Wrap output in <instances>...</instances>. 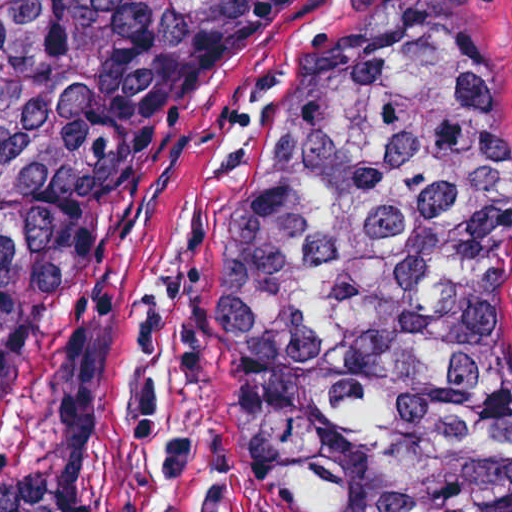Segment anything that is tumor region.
<instances>
[{
	"label": "tumor region",
	"instance_id": "tumor-region-1",
	"mask_svg": "<svg viewBox=\"0 0 512 512\" xmlns=\"http://www.w3.org/2000/svg\"><path fill=\"white\" fill-rule=\"evenodd\" d=\"M290 0H0V398L142 124ZM210 347L272 512H512V105L450 55L334 61L217 232ZM143 271L58 357L60 452L0 512H79Z\"/></svg>",
	"mask_w": 512,
	"mask_h": 512
}]
</instances>
